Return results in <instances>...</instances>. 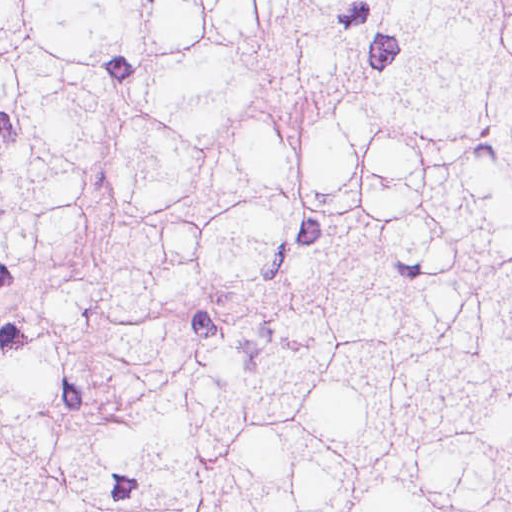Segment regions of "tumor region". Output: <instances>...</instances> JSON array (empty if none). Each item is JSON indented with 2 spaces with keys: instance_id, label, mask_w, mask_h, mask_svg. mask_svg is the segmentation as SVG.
<instances>
[{
  "instance_id": "1",
  "label": "tumor region",
  "mask_w": 512,
  "mask_h": 512,
  "mask_svg": "<svg viewBox=\"0 0 512 512\" xmlns=\"http://www.w3.org/2000/svg\"><path fill=\"white\" fill-rule=\"evenodd\" d=\"M1 512H512V0H1Z\"/></svg>"
}]
</instances>
